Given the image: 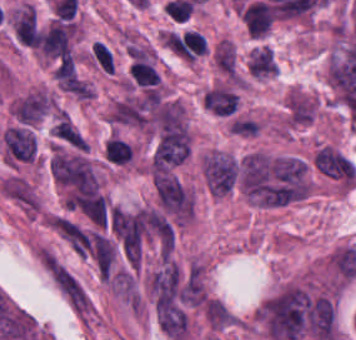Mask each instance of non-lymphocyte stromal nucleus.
<instances>
[{"mask_svg":"<svg viewBox=\"0 0 356 340\" xmlns=\"http://www.w3.org/2000/svg\"><path fill=\"white\" fill-rule=\"evenodd\" d=\"M3 197L24 216L34 217L39 212V200L24 179L10 175L0 182Z\"/></svg>","mask_w":356,"mask_h":340,"instance_id":"dd21d789","label":"non-lymphocyte stromal nucleus"},{"mask_svg":"<svg viewBox=\"0 0 356 340\" xmlns=\"http://www.w3.org/2000/svg\"><path fill=\"white\" fill-rule=\"evenodd\" d=\"M239 104L232 88L214 86L203 94V105L213 114L230 117Z\"/></svg>","mask_w":356,"mask_h":340,"instance_id":"a72fc3eb","label":"non-lymphocyte stromal nucleus"},{"mask_svg":"<svg viewBox=\"0 0 356 340\" xmlns=\"http://www.w3.org/2000/svg\"><path fill=\"white\" fill-rule=\"evenodd\" d=\"M14 30L23 39H35L34 11L28 4L14 14Z\"/></svg>","mask_w":356,"mask_h":340,"instance_id":"3746e769","label":"non-lymphocyte stromal nucleus"},{"mask_svg":"<svg viewBox=\"0 0 356 340\" xmlns=\"http://www.w3.org/2000/svg\"><path fill=\"white\" fill-rule=\"evenodd\" d=\"M90 52L96 62L107 72H114L112 57L106 44L103 42H94L90 47Z\"/></svg>","mask_w":356,"mask_h":340,"instance_id":"fc2b8d12","label":"non-lymphocyte stromal nucleus"}]
</instances>
